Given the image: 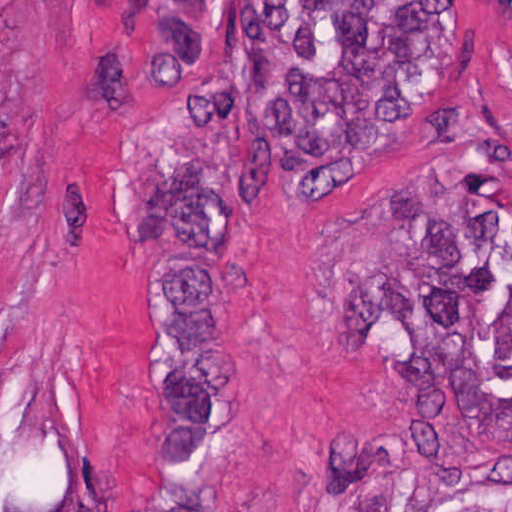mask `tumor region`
Segmentation results:
<instances>
[{"instance_id": "e687c5a6", "label": "tumor region", "mask_w": 512, "mask_h": 512, "mask_svg": "<svg viewBox=\"0 0 512 512\" xmlns=\"http://www.w3.org/2000/svg\"><path fill=\"white\" fill-rule=\"evenodd\" d=\"M144 0L126 29L138 204L157 253L162 499L227 512L238 392L240 217L262 194L330 181L376 154L454 62L465 0ZM6 60L0 34V118ZM0 512H78L70 485L21 479L0 455Z\"/></svg>"}]
</instances>
